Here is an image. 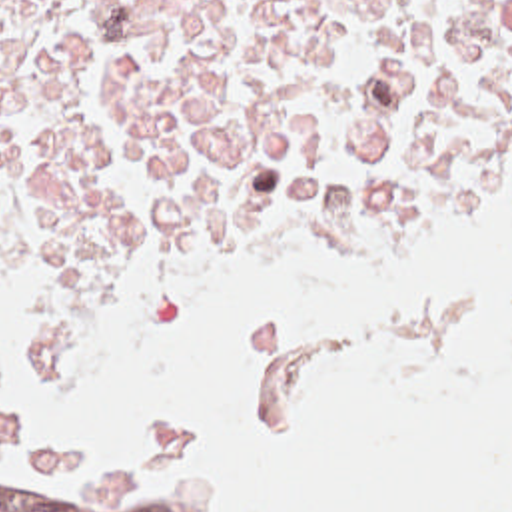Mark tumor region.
<instances>
[{
	"mask_svg": "<svg viewBox=\"0 0 512 512\" xmlns=\"http://www.w3.org/2000/svg\"><path fill=\"white\" fill-rule=\"evenodd\" d=\"M0 512H231L111 462L57 466L25 484H0Z\"/></svg>",
	"mask_w": 512,
	"mask_h": 512,
	"instance_id": "obj_1",
	"label": "tumor region"
}]
</instances>
